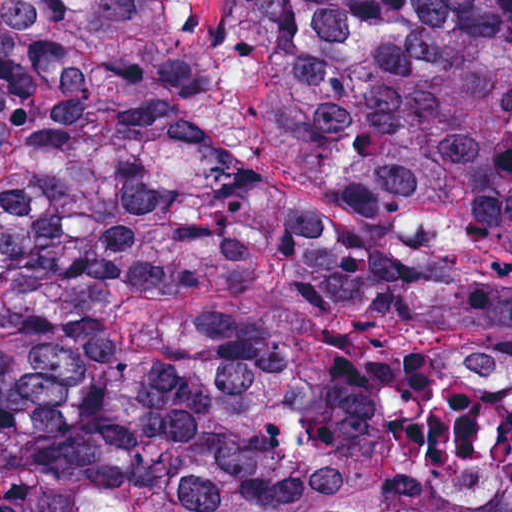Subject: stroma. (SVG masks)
<instances>
[{"label": "stroma", "instance_id": "35a3bbf8", "mask_svg": "<svg viewBox=\"0 0 512 512\" xmlns=\"http://www.w3.org/2000/svg\"><path fill=\"white\" fill-rule=\"evenodd\" d=\"M176 14L203 60L217 69V143L242 163L269 158L263 127L273 83V63L263 44L236 38L218 14V0H176ZM455 267L512 283V261L470 254Z\"/></svg>", "mask_w": 512, "mask_h": 512}]
</instances>
